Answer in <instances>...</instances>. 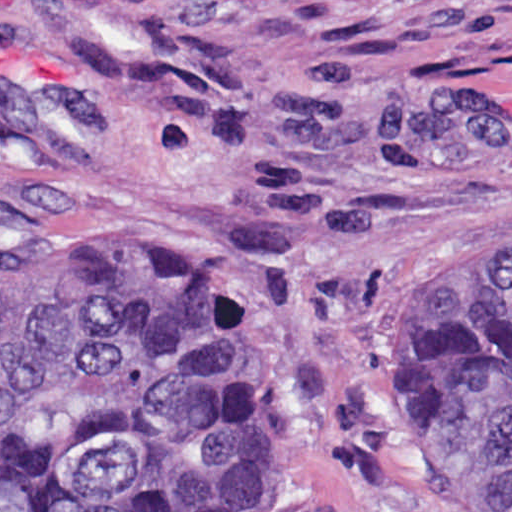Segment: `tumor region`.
Wrapping results in <instances>:
<instances>
[{"label": "tumor region", "mask_w": 512, "mask_h": 512, "mask_svg": "<svg viewBox=\"0 0 512 512\" xmlns=\"http://www.w3.org/2000/svg\"><path fill=\"white\" fill-rule=\"evenodd\" d=\"M173 266L82 242L0 246V512H208L279 466V383ZM446 512H512V208L465 228L429 356Z\"/></svg>", "instance_id": "e687c5a6"}]
</instances>
